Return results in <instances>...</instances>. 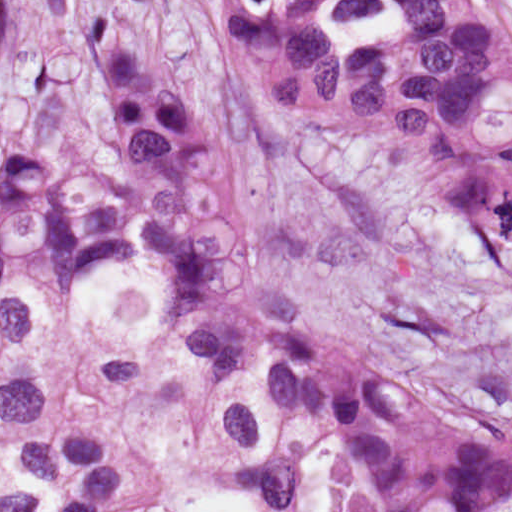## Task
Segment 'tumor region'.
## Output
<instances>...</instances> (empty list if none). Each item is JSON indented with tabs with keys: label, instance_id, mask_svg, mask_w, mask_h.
<instances>
[{
	"label": "tumor region",
	"instance_id": "tumor-region-1",
	"mask_svg": "<svg viewBox=\"0 0 512 512\" xmlns=\"http://www.w3.org/2000/svg\"><path fill=\"white\" fill-rule=\"evenodd\" d=\"M159 0H96L78 71L94 119L65 141L0 110V512H115L133 439L52 419L26 364L148 391L84 328L102 285L152 294L227 472L300 501L317 428L336 512H499L512 439L376 361L263 270L242 197L161 26ZM266 100L350 141L401 199L489 227L512 264V7L505 0H213Z\"/></svg>",
	"mask_w": 512,
	"mask_h": 512
}]
</instances>
